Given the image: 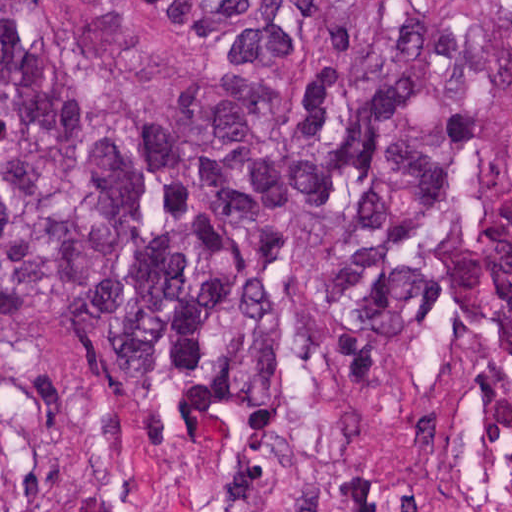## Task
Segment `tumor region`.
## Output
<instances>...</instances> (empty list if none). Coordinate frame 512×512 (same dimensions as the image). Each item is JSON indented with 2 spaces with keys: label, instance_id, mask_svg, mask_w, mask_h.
<instances>
[{
  "label": "tumor region",
  "instance_id": "obj_1",
  "mask_svg": "<svg viewBox=\"0 0 512 512\" xmlns=\"http://www.w3.org/2000/svg\"><path fill=\"white\" fill-rule=\"evenodd\" d=\"M445 314L512 377V0H0V327L102 337L153 431ZM0 512H25L0 456Z\"/></svg>",
  "mask_w": 512,
  "mask_h": 512
}]
</instances>
